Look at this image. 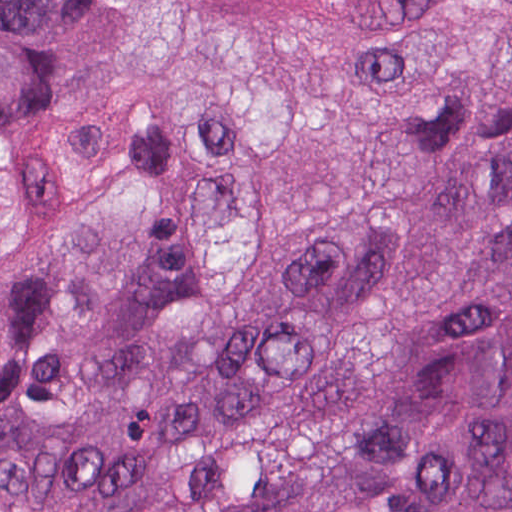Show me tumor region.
Returning <instances> with one entry per match:
<instances>
[{
    "label": "tumor region",
    "mask_w": 512,
    "mask_h": 512,
    "mask_svg": "<svg viewBox=\"0 0 512 512\" xmlns=\"http://www.w3.org/2000/svg\"><path fill=\"white\" fill-rule=\"evenodd\" d=\"M0 512H512V0H0Z\"/></svg>",
    "instance_id": "tumor-region-1"
}]
</instances>
